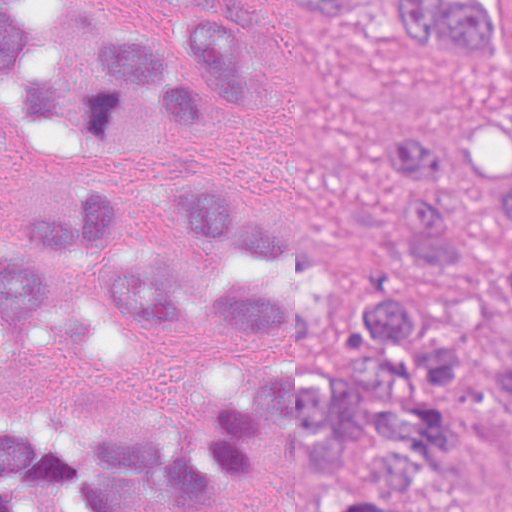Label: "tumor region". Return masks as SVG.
Segmentation results:
<instances>
[{
    "label": "tumor region",
    "instance_id": "tumor-region-1",
    "mask_svg": "<svg viewBox=\"0 0 512 512\" xmlns=\"http://www.w3.org/2000/svg\"><path fill=\"white\" fill-rule=\"evenodd\" d=\"M328 19L348 0H283ZM512 2V0H510ZM253 0H0V128L74 158H146L225 128L236 100L267 95ZM400 35L471 65L495 59L482 0H397ZM374 171L391 182L379 242L391 262L466 279L447 312L405 295L357 303L362 370L321 362L328 339L248 265L307 249L276 214L237 199L225 178L178 174L176 218L207 242L196 261L119 247L136 229L116 187L94 182L63 212L0 239V359L30 339L73 259H99L107 309L146 325L247 321L285 336L275 375L238 389L205 445L162 429L70 425L54 408L0 418V512L44 493L75 512H135L192 496L258 458L283 433L332 493L323 512H422L451 467L455 392L512 402V366H478L471 328L512 303L508 232L487 241L461 208L446 135L402 120L383 128Z\"/></svg>",
    "mask_w": 512,
    "mask_h": 512
}]
</instances>
